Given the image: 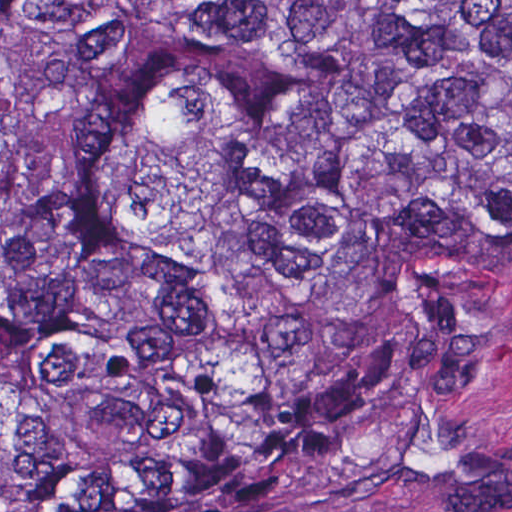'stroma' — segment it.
Returning <instances> with one entry per match:
<instances>
[{
    "mask_svg": "<svg viewBox=\"0 0 512 512\" xmlns=\"http://www.w3.org/2000/svg\"><path fill=\"white\" fill-rule=\"evenodd\" d=\"M319 512H512V308L413 396L361 478Z\"/></svg>",
    "mask_w": 512,
    "mask_h": 512,
    "instance_id": "stroma-1",
    "label": "stroma"
}]
</instances>
